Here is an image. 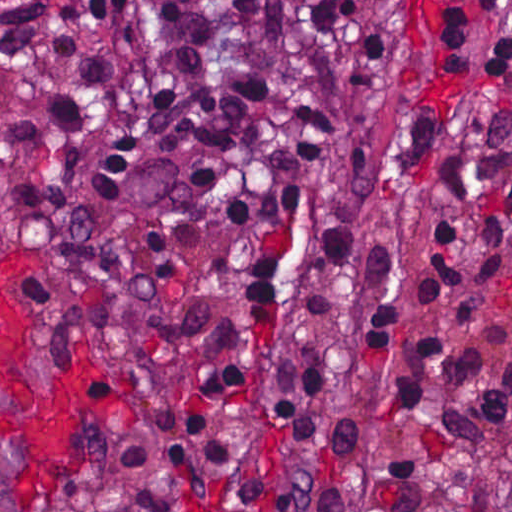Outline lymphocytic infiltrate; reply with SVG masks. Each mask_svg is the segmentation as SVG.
I'll return each instance as SVG.
<instances>
[{"label": "lymphocytic infiltrate", "mask_w": 512, "mask_h": 512, "mask_svg": "<svg viewBox=\"0 0 512 512\" xmlns=\"http://www.w3.org/2000/svg\"><path fill=\"white\" fill-rule=\"evenodd\" d=\"M442 465H378L371 512H427ZM355 471H217L165 420L136 435L93 485L98 512H347ZM454 512H512V471H484L461 490Z\"/></svg>", "instance_id": "obj_1"}]
</instances>
